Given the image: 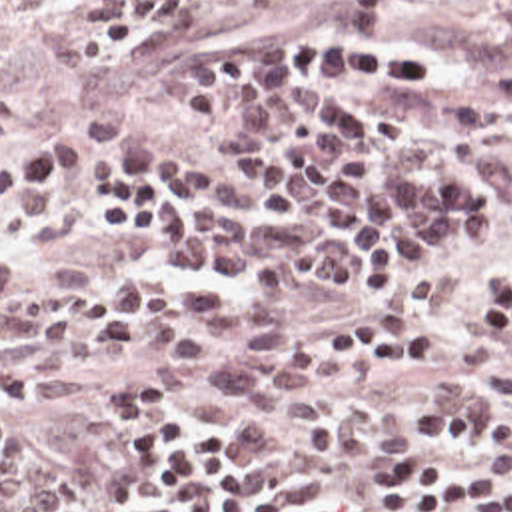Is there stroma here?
<instances>
[{
  "mask_svg": "<svg viewBox=\"0 0 512 512\" xmlns=\"http://www.w3.org/2000/svg\"><path fill=\"white\" fill-rule=\"evenodd\" d=\"M92 2L0 0V143L26 161L32 141L46 133L78 131L88 141V157L58 175L60 201L54 213L36 227L0 219V243L22 269L84 293H98L112 273H128L162 287L212 291L230 303H264L246 287L174 269L116 241L102 227L88 207V175L98 159V141L86 121L94 115L144 131L166 157L204 155L222 145L218 135L184 127L158 91L138 85L136 69L154 67L166 85H182L194 55L320 26L338 18L344 0H266L258 6L188 0V18L152 39L112 75H88L78 61V41ZM400 20L465 77L512 95V0L410 2L400 8ZM503 279H512V237L491 251L473 279L443 305L404 301L390 309H370L330 283L312 285L290 301L268 303L286 331L312 357L328 363L324 341L376 323H412L433 333V349L416 359L386 367L332 363L336 397L374 401L380 447L368 453H344L322 439L298 437L276 413H252L228 401L214 379L196 385L192 395L168 397L182 417L216 423L242 453L330 497L340 512H400L374 487V463L384 451L412 441L408 417L429 401L433 381L465 375L497 401L501 381L512 377V343H493L489 307L481 297L487 283ZM0 345L22 353V345L2 333ZM70 363L90 371L88 389L64 403H12L6 397L8 427L28 433L42 461L62 473L66 512H144L142 493L122 485L118 475V435L126 411L114 409L108 399L118 377H144V367L140 361L104 357H76ZM433 445L453 459H491L485 441L467 445L439 437Z\"/></svg>",
  "mask_w": 512,
  "mask_h": 512,
  "instance_id": "obj_1",
  "label": "stroma"
}]
</instances>
